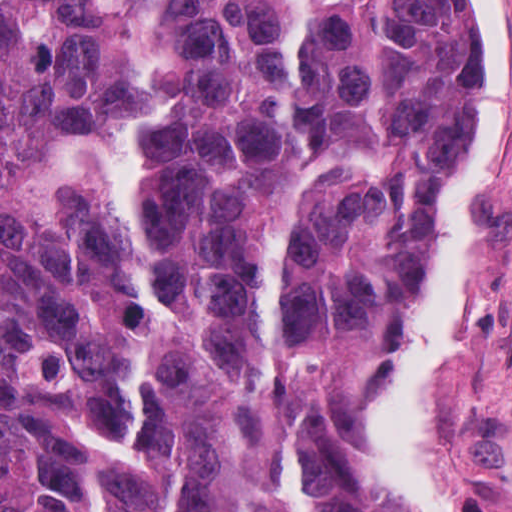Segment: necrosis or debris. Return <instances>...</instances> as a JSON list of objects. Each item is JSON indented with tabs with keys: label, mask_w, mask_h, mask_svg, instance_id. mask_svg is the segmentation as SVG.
Wrapping results in <instances>:
<instances>
[{
	"label": "necrosis or debris",
	"mask_w": 512,
	"mask_h": 512,
	"mask_svg": "<svg viewBox=\"0 0 512 512\" xmlns=\"http://www.w3.org/2000/svg\"><path fill=\"white\" fill-rule=\"evenodd\" d=\"M484 512H512V504L502 495L476 485Z\"/></svg>",
	"instance_id": "4bbe7bcc"
}]
</instances>
